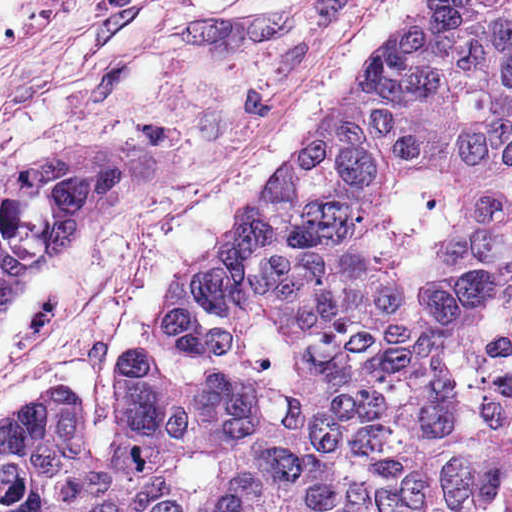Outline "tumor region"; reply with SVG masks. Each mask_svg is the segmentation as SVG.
<instances>
[{
	"mask_svg": "<svg viewBox=\"0 0 512 512\" xmlns=\"http://www.w3.org/2000/svg\"><path fill=\"white\" fill-rule=\"evenodd\" d=\"M425 8L512 201V0Z\"/></svg>",
	"mask_w": 512,
	"mask_h": 512,
	"instance_id": "1",
	"label": "tumor region"
}]
</instances>
